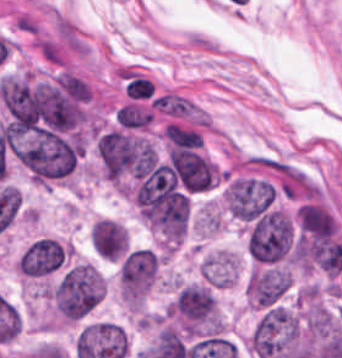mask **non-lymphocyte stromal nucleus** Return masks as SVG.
<instances>
[{
	"instance_id": "dd21d789",
	"label": "non-lymphocyte stromal nucleus",
	"mask_w": 342,
	"mask_h": 358,
	"mask_svg": "<svg viewBox=\"0 0 342 358\" xmlns=\"http://www.w3.org/2000/svg\"><path fill=\"white\" fill-rule=\"evenodd\" d=\"M163 138L177 148L195 149L202 145L201 137L195 130L170 122L163 130Z\"/></svg>"
}]
</instances>
